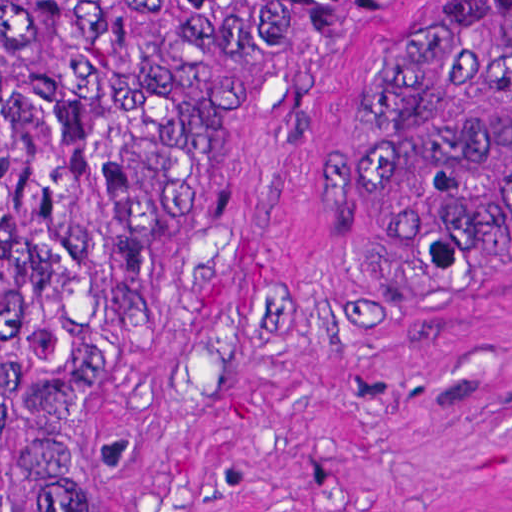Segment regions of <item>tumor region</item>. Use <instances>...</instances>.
<instances>
[{
  "label": "tumor region",
  "mask_w": 512,
  "mask_h": 512,
  "mask_svg": "<svg viewBox=\"0 0 512 512\" xmlns=\"http://www.w3.org/2000/svg\"><path fill=\"white\" fill-rule=\"evenodd\" d=\"M253 1L1 0V512L79 509ZM511 241L512 0H397L330 187L343 316L397 318Z\"/></svg>",
  "instance_id": "1"
}]
</instances>
